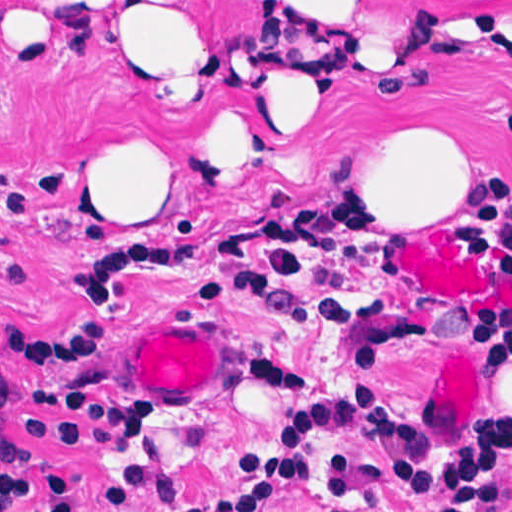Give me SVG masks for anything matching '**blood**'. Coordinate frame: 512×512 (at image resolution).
Returning a JSON list of instances; mask_svg holds the SVG:
<instances>
[{
  "instance_id": "blood-1",
  "label": "blood",
  "mask_w": 512,
  "mask_h": 512,
  "mask_svg": "<svg viewBox=\"0 0 512 512\" xmlns=\"http://www.w3.org/2000/svg\"><path fill=\"white\" fill-rule=\"evenodd\" d=\"M401 272L436 302L465 303L472 309L512 308V274L484 262L444 229L407 236Z\"/></svg>"
}]
</instances>
